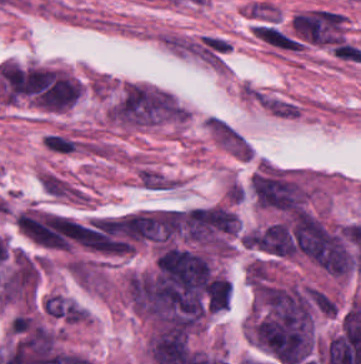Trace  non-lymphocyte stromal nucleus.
I'll return each instance as SVG.
<instances>
[{"instance_id": "3", "label": "non-lymphocyte stromal nucleus", "mask_w": 361, "mask_h": 364, "mask_svg": "<svg viewBox=\"0 0 361 364\" xmlns=\"http://www.w3.org/2000/svg\"><path fill=\"white\" fill-rule=\"evenodd\" d=\"M42 142L53 153L65 154L78 148L77 138L55 132H48Z\"/></svg>"}, {"instance_id": "1", "label": "non-lymphocyte stromal nucleus", "mask_w": 361, "mask_h": 364, "mask_svg": "<svg viewBox=\"0 0 361 364\" xmlns=\"http://www.w3.org/2000/svg\"><path fill=\"white\" fill-rule=\"evenodd\" d=\"M109 114L123 121L149 123L182 118L183 110L168 91L133 83L125 88Z\"/></svg>"}, {"instance_id": "2", "label": "non-lymphocyte stromal nucleus", "mask_w": 361, "mask_h": 364, "mask_svg": "<svg viewBox=\"0 0 361 364\" xmlns=\"http://www.w3.org/2000/svg\"><path fill=\"white\" fill-rule=\"evenodd\" d=\"M206 127L215 140L231 154L247 161L253 158L252 142L223 116L210 115Z\"/></svg>"}]
</instances>
